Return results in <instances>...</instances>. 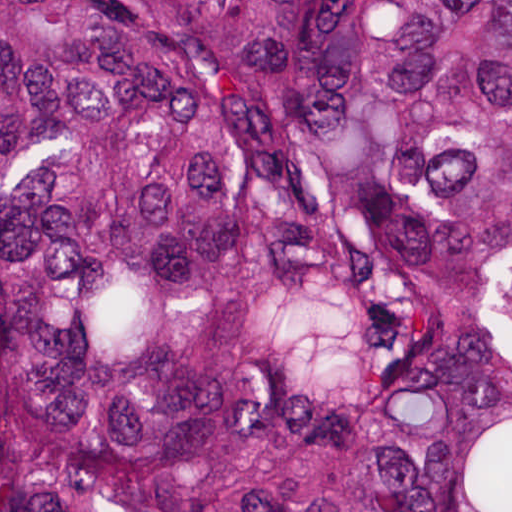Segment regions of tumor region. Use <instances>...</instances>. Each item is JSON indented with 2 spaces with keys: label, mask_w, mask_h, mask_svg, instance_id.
<instances>
[{
  "label": "tumor region",
  "mask_w": 512,
  "mask_h": 512,
  "mask_svg": "<svg viewBox=\"0 0 512 512\" xmlns=\"http://www.w3.org/2000/svg\"><path fill=\"white\" fill-rule=\"evenodd\" d=\"M0 512H512V1H0Z\"/></svg>",
  "instance_id": "1"
}]
</instances>
